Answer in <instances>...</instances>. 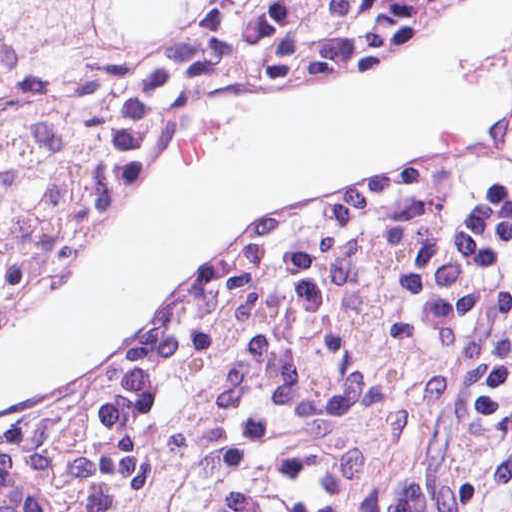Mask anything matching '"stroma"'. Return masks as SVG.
<instances>
[{"label":"stroma","mask_w":512,"mask_h":512,"mask_svg":"<svg viewBox=\"0 0 512 512\" xmlns=\"http://www.w3.org/2000/svg\"><path fill=\"white\" fill-rule=\"evenodd\" d=\"M0 1H384L303 58L255 74L302 75L359 53L395 32L409 16L433 1L512 0ZM119 210L77 244L30 303L79 262ZM13 321L0 329V337ZM91 385L25 408L32 477L47 512H75V449ZM398 512H512V278L497 306L478 324L467 355L419 433L407 463L405 460Z\"/></svg>","instance_id":"35a3bbf8"}]
</instances>
